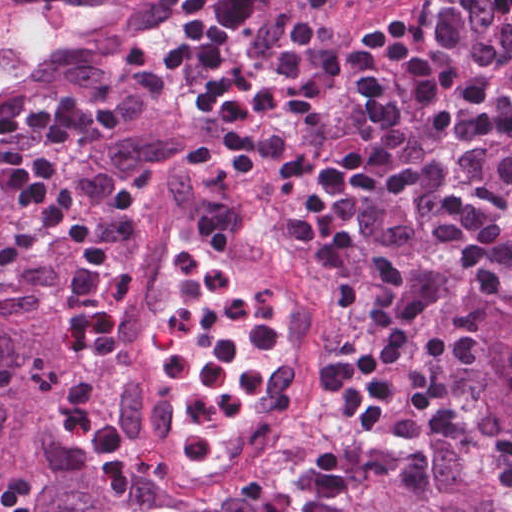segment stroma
Masks as SVG:
<instances>
[{
  "label": "stroma",
  "instance_id": "35a3bbf8",
  "mask_svg": "<svg viewBox=\"0 0 512 512\" xmlns=\"http://www.w3.org/2000/svg\"><path fill=\"white\" fill-rule=\"evenodd\" d=\"M446 1L449 0H391L369 12H362L349 0H327L332 10L364 33L380 54L382 133L371 153L376 158L388 136L393 95L400 77V71L380 45L389 31L416 13ZM86 62L107 69V81L101 88H87L70 80L74 77L65 76L81 70ZM67 96L106 109L115 115L118 126L107 141L90 150L74 151L50 165L62 184L79 194L88 205L100 235L111 240L123 233L152 196L167 194L168 170H174L177 163H181L200 194L199 203L212 214L234 220L251 230L308 277L325 262L289 229L281 195L250 159L234 156L167 110L147 64L144 29L109 44L69 71L34 85L10 105L28 106ZM122 135L176 137L184 141V150L173 158L148 159L132 169H113L102 150ZM15 223V220L0 218V239L10 233ZM74 268V251L69 239H52L38 246L0 274V310L21 316L52 318L66 325L63 307ZM315 281L335 298L340 314L335 362L345 369L353 384L361 417L376 446L373 467L338 505L327 512H348L364 488L385 475L399 479L427 498L426 475L400 448L374 394L363 283ZM99 360L100 354L83 352L75 363L94 381L96 388ZM333 411L322 389L311 418L329 421ZM47 419L79 451L63 422L51 411ZM127 469L116 477L104 476L86 460L84 468L69 472L81 477L92 493L111 510L119 512L116 489Z\"/></svg>",
  "mask_w": 512,
  "mask_h": 512
}]
</instances>
